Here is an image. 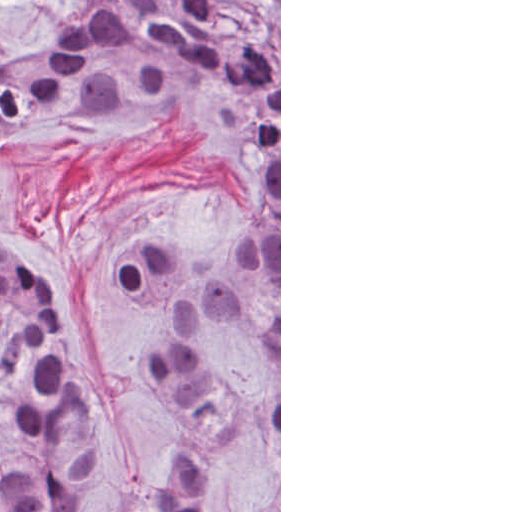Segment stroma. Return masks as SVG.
I'll list each match as a JSON object with an SVG mask.
<instances>
[{
	"label": "stroma",
	"mask_w": 512,
	"mask_h": 512,
	"mask_svg": "<svg viewBox=\"0 0 512 512\" xmlns=\"http://www.w3.org/2000/svg\"><path fill=\"white\" fill-rule=\"evenodd\" d=\"M259 8L279 39V367L218 329V359L237 414L235 462L205 512H248L279 492L281 512V0H215ZM95 0H0V65L67 42ZM267 190L200 130L165 114H120L41 132L10 157L0 186V241L45 281L65 313L72 371L88 405L103 509L128 512L187 433V413L140 350L169 320L123 293L116 263L145 236L188 239L189 274L211 276L252 316L266 318L264 288L241 241ZM15 433L0 406V460ZM222 454V453H221ZM225 470L230 459L222 454Z\"/></svg>",
	"instance_id": "1"
}]
</instances>
